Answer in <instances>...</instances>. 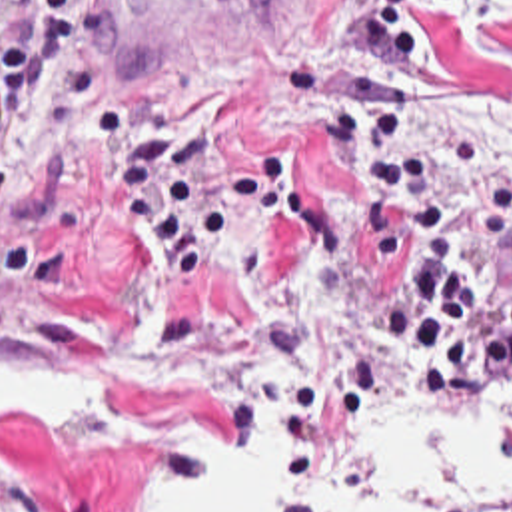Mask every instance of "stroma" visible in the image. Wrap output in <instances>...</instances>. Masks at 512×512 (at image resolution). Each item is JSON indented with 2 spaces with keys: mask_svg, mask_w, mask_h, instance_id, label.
<instances>
[{
  "mask_svg": "<svg viewBox=\"0 0 512 512\" xmlns=\"http://www.w3.org/2000/svg\"><path fill=\"white\" fill-rule=\"evenodd\" d=\"M431 1L265 0L231 31L106 83L125 109L203 133L219 153L291 163V211L241 233L195 291L121 211L100 153L60 111L26 105L0 141V357L90 359L127 377V393L106 413L0 429V512H123L135 475L195 481L197 435L239 453L265 405L287 512L313 511L361 413L417 399L453 425L512 417V367L491 371L465 409L407 389L381 341L401 277L369 273V187L331 155L335 111L351 91H381ZM495 37L512 47V11ZM443 193L469 283H512V249L445 177ZM453 512H512V477Z\"/></svg>",
  "mask_w": 512,
  "mask_h": 512,
  "instance_id": "stroma-1",
  "label": "stroma"
}]
</instances>
